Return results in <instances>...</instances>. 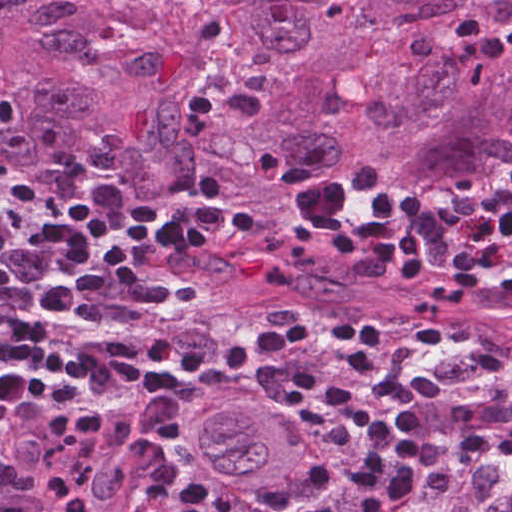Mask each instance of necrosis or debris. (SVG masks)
<instances>
[{
  "instance_id": "1",
  "label": "necrosis or debris",
  "mask_w": 512,
  "mask_h": 512,
  "mask_svg": "<svg viewBox=\"0 0 512 512\" xmlns=\"http://www.w3.org/2000/svg\"><path fill=\"white\" fill-rule=\"evenodd\" d=\"M199 44L200 84L184 119L187 135L224 124L240 127L256 120L266 90L283 81V71L247 43L240 22L216 0H166Z\"/></svg>"
}]
</instances>
